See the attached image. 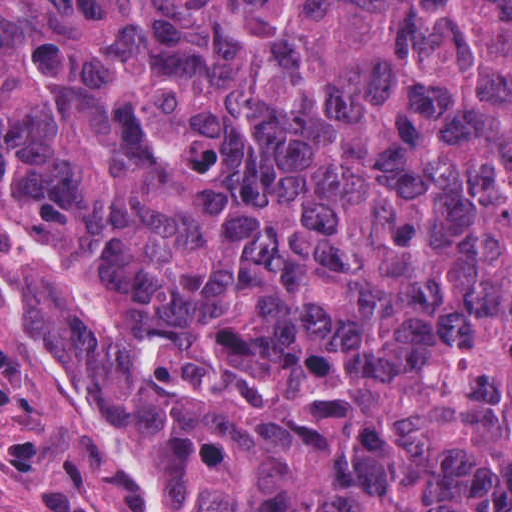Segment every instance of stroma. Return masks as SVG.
<instances>
[{"label":"stroma","mask_w":512,"mask_h":512,"mask_svg":"<svg viewBox=\"0 0 512 512\" xmlns=\"http://www.w3.org/2000/svg\"><path fill=\"white\" fill-rule=\"evenodd\" d=\"M54 239L0 228V512H25L42 471L79 480L112 512H162L146 470L59 374L40 307Z\"/></svg>","instance_id":"1"}]
</instances>
